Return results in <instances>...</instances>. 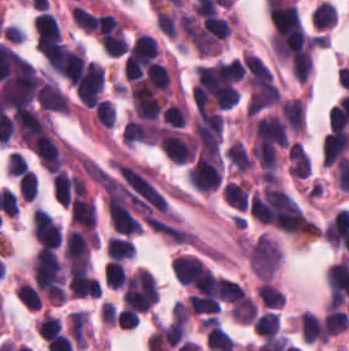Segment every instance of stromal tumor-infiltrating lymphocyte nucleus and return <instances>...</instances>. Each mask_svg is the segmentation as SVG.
Listing matches in <instances>:
<instances>
[{"mask_svg": "<svg viewBox=\"0 0 349 351\" xmlns=\"http://www.w3.org/2000/svg\"><path fill=\"white\" fill-rule=\"evenodd\" d=\"M260 301L266 307H280L284 304L285 293L272 282L263 281L257 286Z\"/></svg>", "mask_w": 349, "mask_h": 351, "instance_id": "obj_11", "label": "stromal tumor-infiltrating lymphocyte nucleus"}, {"mask_svg": "<svg viewBox=\"0 0 349 351\" xmlns=\"http://www.w3.org/2000/svg\"><path fill=\"white\" fill-rule=\"evenodd\" d=\"M126 273L127 271L123 263L112 258L104 269L103 278L107 286L111 288H122Z\"/></svg>", "mask_w": 349, "mask_h": 351, "instance_id": "obj_13", "label": "stromal tumor-infiltrating lymphocyte nucleus"}, {"mask_svg": "<svg viewBox=\"0 0 349 351\" xmlns=\"http://www.w3.org/2000/svg\"><path fill=\"white\" fill-rule=\"evenodd\" d=\"M71 18L76 25L88 32L96 28L97 17L88 8L81 4H73L71 7Z\"/></svg>", "mask_w": 349, "mask_h": 351, "instance_id": "obj_14", "label": "stromal tumor-infiltrating lymphocyte nucleus"}, {"mask_svg": "<svg viewBox=\"0 0 349 351\" xmlns=\"http://www.w3.org/2000/svg\"><path fill=\"white\" fill-rule=\"evenodd\" d=\"M36 39L61 43V34L56 15L48 10L37 13L33 25Z\"/></svg>", "mask_w": 349, "mask_h": 351, "instance_id": "obj_2", "label": "stromal tumor-infiltrating lymphocyte nucleus"}, {"mask_svg": "<svg viewBox=\"0 0 349 351\" xmlns=\"http://www.w3.org/2000/svg\"><path fill=\"white\" fill-rule=\"evenodd\" d=\"M60 332H62V325L60 322L56 317L46 313L38 320L36 324V333L38 337L45 341Z\"/></svg>", "mask_w": 349, "mask_h": 351, "instance_id": "obj_16", "label": "stromal tumor-infiltrating lymphocyte nucleus"}, {"mask_svg": "<svg viewBox=\"0 0 349 351\" xmlns=\"http://www.w3.org/2000/svg\"><path fill=\"white\" fill-rule=\"evenodd\" d=\"M256 334L264 339H271L280 332V322L276 312H262L252 321Z\"/></svg>", "mask_w": 349, "mask_h": 351, "instance_id": "obj_6", "label": "stromal tumor-infiltrating lymphocyte nucleus"}, {"mask_svg": "<svg viewBox=\"0 0 349 351\" xmlns=\"http://www.w3.org/2000/svg\"><path fill=\"white\" fill-rule=\"evenodd\" d=\"M206 343L211 351H233L235 348L231 336L216 326L208 331Z\"/></svg>", "mask_w": 349, "mask_h": 351, "instance_id": "obj_12", "label": "stromal tumor-infiltrating lymphocyte nucleus"}, {"mask_svg": "<svg viewBox=\"0 0 349 351\" xmlns=\"http://www.w3.org/2000/svg\"><path fill=\"white\" fill-rule=\"evenodd\" d=\"M326 336H336L349 326V315L346 311L329 308L323 320Z\"/></svg>", "mask_w": 349, "mask_h": 351, "instance_id": "obj_7", "label": "stromal tumor-infiltrating lymphocyte nucleus"}, {"mask_svg": "<svg viewBox=\"0 0 349 351\" xmlns=\"http://www.w3.org/2000/svg\"><path fill=\"white\" fill-rule=\"evenodd\" d=\"M18 189L23 200H34L37 197L38 181L34 174L28 169L18 181Z\"/></svg>", "mask_w": 349, "mask_h": 351, "instance_id": "obj_18", "label": "stromal tumor-infiltrating lymphocyte nucleus"}, {"mask_svg": "<svg viewBox=\"0 0 349 351\" xmlns=\"http://www.w3.org/2000/svg\"><path fill=\"white\" fill-rule=\"evenodd\" d=\"M337 19L335 4L330 0H323L311 12V20L321 29L331 28Z\"/></svg>", "mask_w": 349, "mask_h": 351, "instance_id": "obj_8", "label": "stromal tumor-infiltrating lymphocyte nucleus"}, {"mask_svg": "<svg viewBox=\"0 0 349 351\" xmlns=\"http://www.w3.org/2000/svg\"><path fill=\"white\" fill-rule=\"evenodd\" d=\"M95 116L101 125L114 127L116 109L107 99H100L93 108Z\"/></svg>", "mask_w": 349, "mask_h": 351, "instance_id": "obj_17", "label": "stromal tumor-infiltrating lymphocyte nucleus"}, {"mask_svg": "<svg viewBox=\"0 0 349 351\" xmlns=\"http://www.w3.org/2000/svg\"><path fill=\"white\" fill-rule=\"evenodd\" d=\"M96 207L91 196L81 195L72 201L70 223L80 229H89L96 225Z\"/></svg>", "mask_w": 349, "mask_h": 351, "instance_id": "obj_1", "label": "stromal tumor-infiltrating lymphocyte nucleus"}, {"mask_svg": "<svg viewBox=\"0 0 349 351\" xmlns=\"http://www.w3.org/2000/svg\"><path fill=\"white\" fill-rule=\"evenodd\" d=\"M16 297L28 308L38 310L42 308L41 293L27 281H19L14 288Z\"/></svg>", "mask_w": 349, "mask_h": 351, "instance_id": "obj_10", "label": "stromal tumor-infiltrating lymphocyte nucleus"}, {"mask_svg": "<svg viewBox=\"0 0 349 351\" xmlns=\"http://www.w3.org/2000/svg\"><path fill=\"white\" fill-rule=\"evenodd\" d=\"M186 107L183 101L170 103L164 109V123L171 128H181L185 125Z\"/></svg>", "mask_w": 349, "mask_h": 351, "instance_id": "obj_15", "label": "stromal tumor-infiltrating lymphocyte nucleus"}, {"mask_svg": "<svg viewBox=\"0 0 349 351\" xmlns=\"http://www.w3.org/2000/svg\"><path fill=\"white\" fill-rule=\"evenodd\" d=\"M52 189L58 201L68 207L76 191L71 174L62 169L56 172L52 176Z\"/></svg>", "mask_w": 349, "mask_h": 351, "instance_id": "obj_4", "label": "stromal tumor-infiltrating lymphocyte nucleus"}, {"mask_svg": "<svg viewBox=\"0 0 349 351\" xmlns=\"http://www.w3.org/2000/svg\"><path fill=\"white\" fill-rule=\"evenodd\" d=\"M68 333L78 347H86L89 339V318L84 311L72 312L68 316Z\"/></svg>", "mask_w": 349, "mask_h": 351, "instance_id": "obj_3", "label": "stromal tumor-infiltrating lymphocyte nucleus"}, {"mask_svg": "<svg viewBox=\"0 0 349 351\" xmlns=\"http://www.w3.org/2000/svg\"><path fill=\"white\" fill-rule=\"evenodd\" d=\"M134 252L133 243L128 237L111 235L108 237L106 256L110 259L125 260Z\"/></svg>", "mask_w": 349, "mask_h": 351, "instance_id": "obj_9", "label": "stromal tumor-infiltrating lymphocyte nucleus"}, {"mask_svg": "<svg viewBox=\"0 0 349 351\" xmlns=\"http://www.w3.org/2000/svg\"><path fill=\"white\" fill-rule=\"evenodd\" d=\"M187 300L192 313L209 316H217L221 304L220 298L205 293H191Z\"/></svg>", "mask_w": 349, "mask_h": 351, "instance_id": "obj_5", "label": "stromal tumor-infiltrating lymphocyte nucleus"}, {"mask_svg": "<svg viewBox=\"0 0 349 351\" xmlns=\"http://www.w3.org/2000/svg\"><path fill=\"white\" fill-rule=\"evenodd\" d=\"M29 168L23 155L18 152L8 154L6 171L9 177H20Z\"/></svg>", "mask_w": 349, "mask_h": 351, "instance_id": "obj_19", "label": "stromal tumor-infiltrating lymphocyte nucleus"}, {"mask_svg": "<svg viewBox=\"0 0 349 351\" xmlns=\"http://www.w3.org/2000/svg\"><path fill=\"white\" fill-rule=\"evenodd\" d=\"M171 314L173 316L174 321L188 323L191 312L185 301L177 300L172 305Z\"/></svg>", "mask_w": 349, "mask_h": 351, "instance_id": "obj_20", "label": "stromal tumor-infiltrating lymphocyte nucleus"}]
</instances>
